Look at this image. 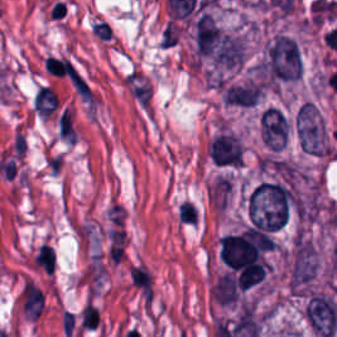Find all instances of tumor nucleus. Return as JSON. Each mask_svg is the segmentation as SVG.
I'll list each match as a JSON object with an SVG mask.
<instances>
[{
    "mask_svg": "<svg viewBox=\"0 0 337 337\" xmlns=\"http://www.w3.org/2000/svg\"><path fill=\"white\" fill-rule=\"evenodd\" d=\"M294 203V195L283 182L261 180L246 194L247 229L276 231L285 225Z\"/></svg>",
    "mask_w": 337,
    "mask_h": 337,
    "instance_id": "obj_1",
    "label": "tumor nucleus"
},
{
    "mask_svg": "<svg viewBox=\"0 0 337 337\" xmlns=\"http://www.w3.org/2000/svg\"><path fill=\"white\" fill-rule=\"evenodd\" d=\"M208 154L218 166H241V141L232 133H218L208 146Z\"/></svg>",
    "mask_w": 337,
    "mask_h": 337,
    "instance_id": "obj_3",
    "label": "tumor nucleus"
},
{
    "mask_svg": "<svg viewBox=\"0 0 337 337\" xmlns=\"http://www.w3.org/2000/svg\"><path fill=\"white\" fill-rule=\"evenodd\" d=\"M259 134L265 147L277 150L285 143L286 121L279 109L269 105L259 115Z\"/></svg>",
    "mask_w": 337,
    "mask_h": 337,
    "instance_id": "obj_4",
    "label": "tumor nucleus"
},
{
    "mask_svg": "<svg viewBox=\"0 0 337 337\" xmlns=\"http://www.w3.org/2000/svg\"><path fill=\"white\" fill-rule=\"evenodd\" d=\"M324 125L313 104L303 103L295 119V135L300 149L322 153Z\"/></svg>",
    "mask_w": 337,
    "mask_h": 337,
    "instance_id": "obj_2",
    "label": "tumor nucleus"
}]
</instances>
